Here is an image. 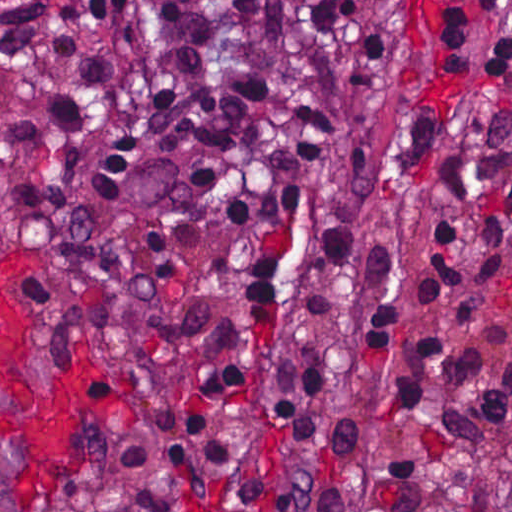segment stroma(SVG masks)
Returning <instances> with one entry per match:
<instances>
[{"mask_svg": "<svg viewBox=\"0 0 512 512\" xmlns=\"http://www.w3.org/2000/svg\"><path fill=\"white\" fill-rule=\"evenodd\" d=\"M512 25V0H391L370 56L356 150L366 173L421 186L448 178L474 124L480 47ZM0 434L22 453L12 512H98L93 485L136 435L168 422L217 471H355L347 512H371L379 464L442 465L427 512H454L484 471H512V423L484 433L288 429L208 409L58 346L34 293L0 264ZM144 512H199L152 509Z\"/></svg>", "mask_w": 512, "mask_h": 512, "instance_id": "stroma-1", "label": "stroma"}]
</instances>
